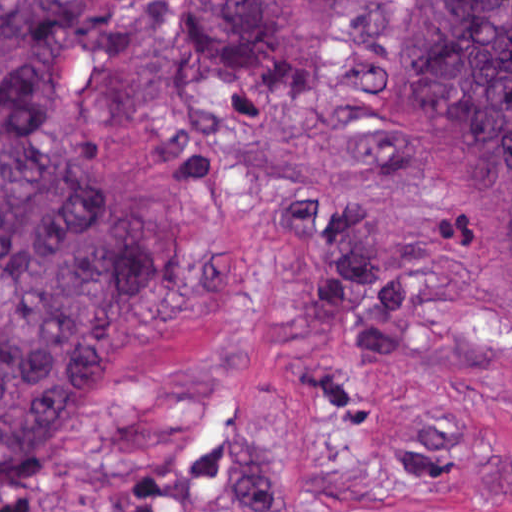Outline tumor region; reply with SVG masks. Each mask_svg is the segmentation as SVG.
<instances>
[{
  "instance_id": "e687c5a6",
  "label": "tumor region",
  "mask_w": 512,
  "mask_h": 512,
  "mask_svg": "<svg viewBox=\"0 0 512 512\" xmlns=\"http://www.w3.org/2000/svg\"><path fill=\"white\" fill-rule=\"evenodd\" d=\"M88 1L0 0V512L20 507L78 381L180 277L147 187L81 170L47 138L42 80ZM152 31L175 78L234 106L304 102L328 43L295 0H152ZM367 90L411 178L512 288V0H384ZM336 180L344 198L270 181L273 229L309 330L355 368L388 367L411 346V278ZM136 476L118 512H269L252 465L206 491Z\"/></svg>"
}]
</instances>
